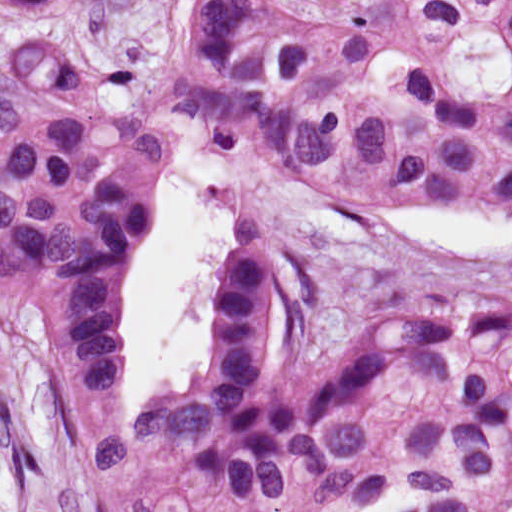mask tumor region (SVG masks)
Returning a JSON list of instances; mask_svg holds the SVG:
<instances>
[{
	"label": "tumor region",
	"mask_w": 512,
	"mask_h": 512,
	"mask_svg": "<svg viewBox=\"0 0 512 512\" xmlns=\"http://www.w3.org/2000/svg\"><path fill=\"white\" fill-rule=\"evenodd\" d=\"M54 0H0L29 10ZM0 309L37 281L34 397L84 512H512V332L384 322L290 376L289 291L243 238L180 390L130 413L121 336L155 168L252 158L352 225L512 210V0H131L2 42Z\"/></svg>",
	"instance_id": "tumor-region-1"
}]
</instances>
